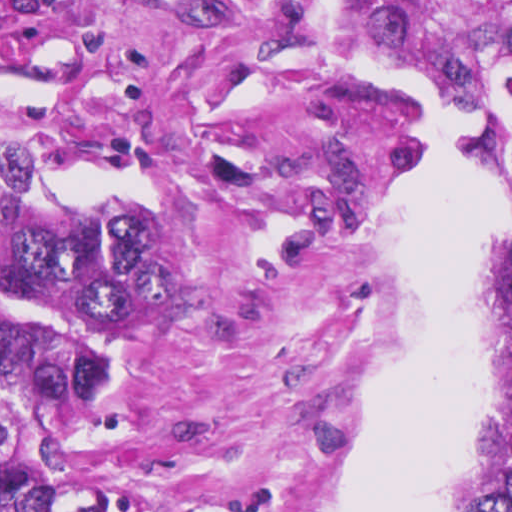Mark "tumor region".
<instances>
[{
  "mask_svg": "<svg viewBox=\"0 0 512 512\" xmlns=\"http://www.w3.org/2000/svg\"><path fill=\"white\" fill-rule=\"evenodd\" d=\"M367 64L399 60L496 107L512 54V0H331ZM499 168L510 250L499 278L490 474L460 512H512V139ZM169 259L153 221L94 209L1 225V512H199L96 476V432L132 363Z\"/></svg>",
  "mask_w": 512,
  "mask_h": 512,
  "instance_id": "e687c5a6",
  "label": "tumor region"
}]
</instances>
